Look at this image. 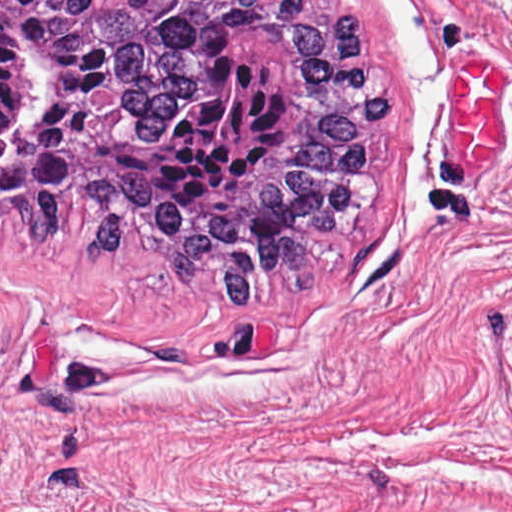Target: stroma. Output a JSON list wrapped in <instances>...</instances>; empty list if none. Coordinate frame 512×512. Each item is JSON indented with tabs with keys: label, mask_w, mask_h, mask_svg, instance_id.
Listing matches in <instances>:
<instances>
[{
	"label": "stroma",
	"mask_w": 512,
	"mask_h": 512,
	"mask_svg": "<svg viewBox=\"0 0 512 512\" xmlns=\"http://www.w3.org/2000/svg\"><path fill=\"white\" fill-rule=\"evenodd\" d=\"M361 10L379 201L242 305L0 225V512H512V0Z\"/></svg>",
	"instance_id": "obj_1"
}]
</instances>
